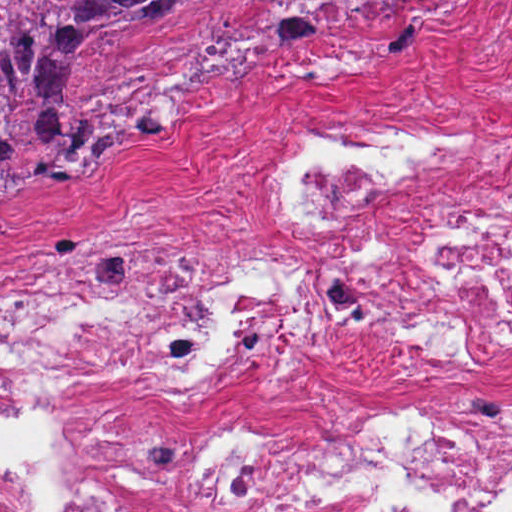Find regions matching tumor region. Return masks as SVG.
<instances>
[{"label":"tumor region","mask_w":512,"mask_h":512,"mask_svg":"<svg viewBox=\"0 0 512 512\" xmlns=\"http://www.w3.org/2000/svg\"><path fill=\"white\" fill-rule=\"evenodd\" d=\"M225 0H0V198L75 184L120 144L178 126L162 113L83 102L74 55L104 36H146Z\"/></svg>","instance_id":"tumor-region-1"}]
</instances>
